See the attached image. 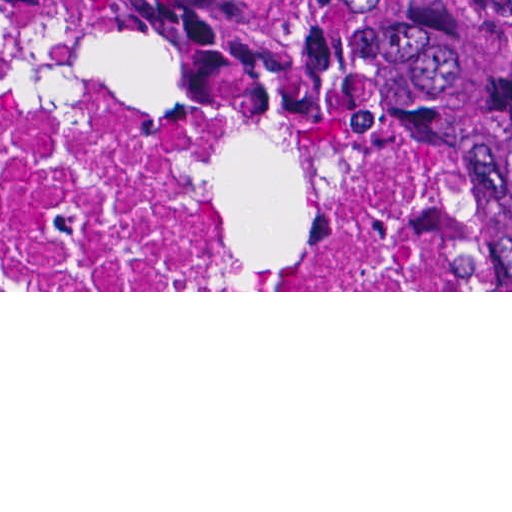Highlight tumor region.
<instances>
[{"label":"tumor region","mask_w":512,"mask_h":512,"mask_svg":"<svg viewBox=\"0 0 512 512\" xmlns=\"http://www.w3.org/2000/svg\"><path fill=\"white\" fill-rule=\"evenodd\" d=\"M238 50L392 113H512V0H22Z\"/></svg>","instance_id":"1"}]
</instances>
